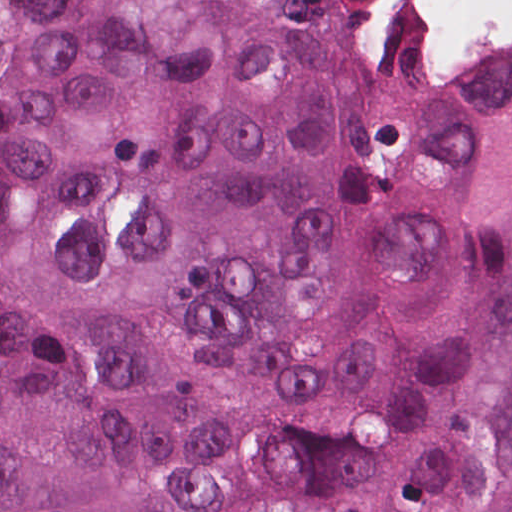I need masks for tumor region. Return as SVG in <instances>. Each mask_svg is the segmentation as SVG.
<instances>
[{"label":"tumor region","instance_id":"obj_1","mask_svg":"<svg viewBox=\"0 0 512 512\" xmlns=\"http://www.w3.org/2000/svg\"><path fill=\"white\" fill-rule=\"evenodd\" d=\"M0 512H512V57L435 80L356 1H34Z\"/></svg>","mask_w":512,"mask_h":512}]
</instances>
